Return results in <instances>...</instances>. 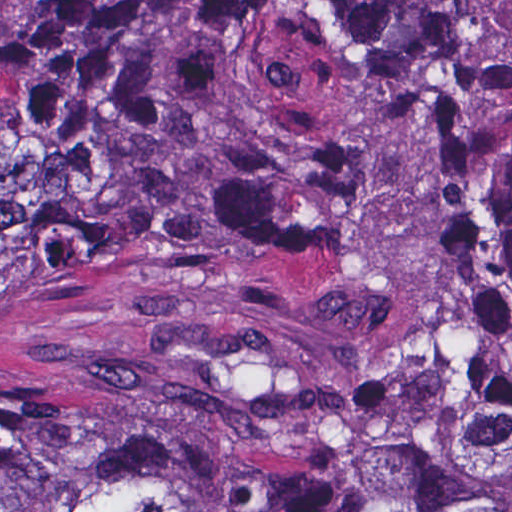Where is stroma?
Here are the masks:
<instances>
[{
	"instance_id": "1",
	"label": "stroma",
	"mask_w": 512,
	"mask_h": 512,
	"mask_svg": "<svg viewBox=\"0 0 512 512\" xmlns=\"http://www.w3.org/2000/svg\"><path fill=\"white\" fill-rule=\"evenodd\" d=\"M38 0H0V29H12L29 16Z\"/></svg>"
}]
</instances>
